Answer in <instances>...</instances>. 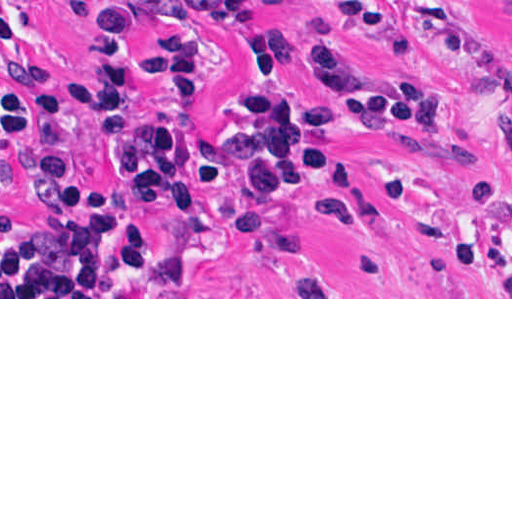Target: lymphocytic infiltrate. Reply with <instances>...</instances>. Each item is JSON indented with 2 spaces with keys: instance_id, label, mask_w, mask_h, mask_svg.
<instances>
[{
  "instance_id": "lymphocytic-infiltrate-1",
  "label": "lymphocytic infiltrate",
  "mask_w": 512,
  "mask_h": 512,
  "mask_svg": "<svg viewBox=\"0 0 512 512\" xmlns=\"http://www.w3.org/2000/svg\"><path fill=\"white\" fill-rule=\"evenodd\" d=\"M37 0H0V41L13 45L28 31ZM82 35L88 72L71 77L76 96L91 107L103 160L129 189L149 196L158 213L190 208L185 151L186 119L156 115L140 103L138 82L146 81L179 101L202 98L211 57L194 33L171 34L143 55L132 50V21L196 18L222 30L255 22L248 0H57ZM255 69L293 63L343 97L340 110L316 120L347 125L361 133L402 138L473 162L477 179L488 177L491 157L462 142L411 135L403 124L448 130L450 110L438 87L357 65L341 31L304 50L291 35L270 36L248 49ZM0 145L12 157L14 179L33 208L26 216L10 208L0 216V273L67 284H154L149 222H135L94 190L77 166L64 105L50 73L27 62L13 68L12 94L0 107ZM234 164L247 192L267 210L286 188L327 163V148L299 126L285 93L246 94L236 102L229 129L214 136L202 160L204 181L226 198V215L236 236L263 252L301 255L315 248L296 243L283 225L248 210L226 175ZM389 205L426 231L448 255L465 220L464 196L449 211L414 176L396 175L386 185ZM347 212L384 233L364 178L347 166L331 170L312 217ZM296 297H324L318 285Z\"/></svg>"
}]
</instances>
